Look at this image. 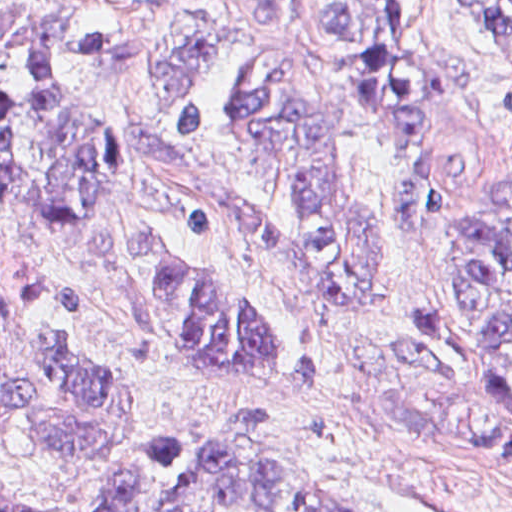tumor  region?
<instances>
[{
  "instance_id": "1",
  "label": "tumor region",
  "mask_w": 512,
  "mask_h": 512,
  "mask_svg": "<svg viewBox=\"0 0 512 512\" xmlns=\"http://www.w3.org/2000/svg\"><path fill=\"white\" fill-rule=\"evenodd\" d=\"M231 1L253 27L287 28L296 16V0ZM473 1L512 42V0ZM72 34L55 12L0 10V201L57 226L88 222L101 262L135 299L145 329L200 374L317 393L324 361L313 335L261 324L224 278L162 233L128 231L104 216L121 197L124 164L66 73ZM154 79L169 95L165 104L182 105L180 139L232 140L262 158L305 229L293 234L209 199L184 206L185 225L253 237L300 268L309 297L376 318L380 248L347 184L342 120L355 107L369 114L394 151L398 224L430 225L442 177L424 134L435 115L466 100V62L413 53L406 0H332L313 39L283 54L224 32L190 33ZM396 346L404 367L389 394L398 419L512 454V168L473 208L452 213L437 289L396 324ZM21 349L23 381L0 385V451L23 434L61 466L103 460L150 400L113 379L80 318L32 325ZM273 413L230 396L223 418L153 446L90 507L5 495L0 512H353L287 454L250 438L248 428L271 423Z\"/></svg>"
}]
</instances>
